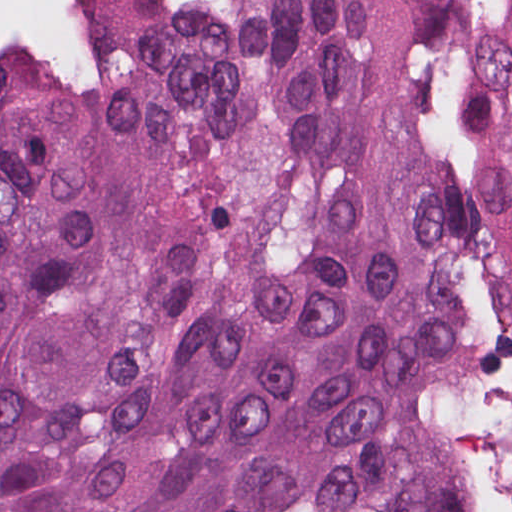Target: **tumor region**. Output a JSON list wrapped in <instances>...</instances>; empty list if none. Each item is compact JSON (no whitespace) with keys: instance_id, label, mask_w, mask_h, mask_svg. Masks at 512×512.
Instances as JSON below:
<instances>
[{"instance_id":"tumor-region-1","label":"tumor region","mask_w":512,"mask_h":512,"mask_svg":"<svg viewBox=\"0 0 512 512\" xmlns=\"http://www.w3.org/2000/svg\"><path fill=\"white\" fill-rule=\"evenodd\" d=\"M94 102L0 54V512H484L428 353L512 337V0H115Z\"/></svg>"}]
</instances>
